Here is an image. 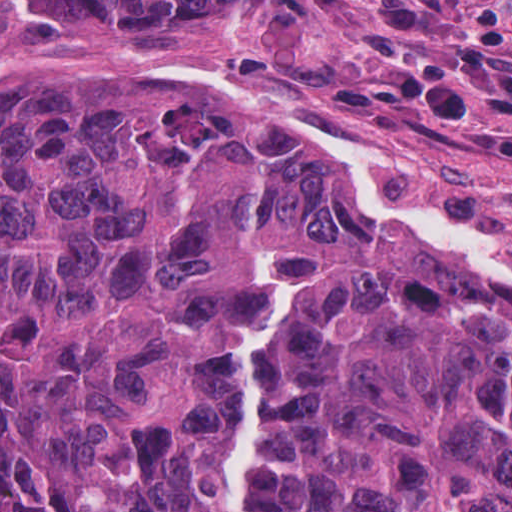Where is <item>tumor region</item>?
<instances>
[{"mask_svg": "<svg viewBox=\"0 0 512 512\" xmlns=\"http://www.w3.org/2000/svg\"><path fill=\"white\" fill-rule=\"evenodd\" d=\"M104 21L232 0H25ZM252 512H512V303L224 90L0 73V491L18 512H230L272 249Z\"/></svg>", "mask_w": 512, "mask_h": 512, "instance_id": "tumor-region-1", "label": "tumor region"}]
</instances>
